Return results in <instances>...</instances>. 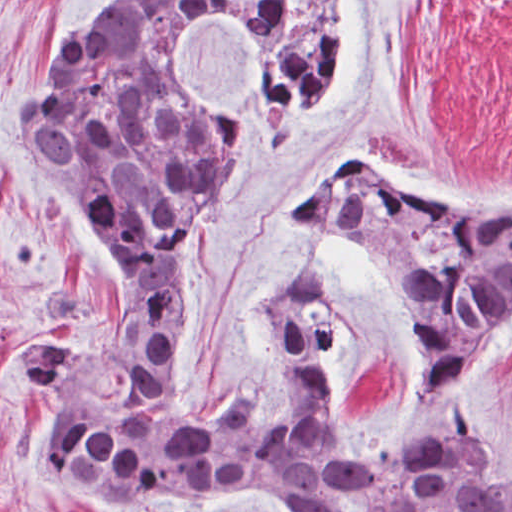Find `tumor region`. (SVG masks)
Instances as JSON below:
<instances>
[{
  "label": "tumor region",
  "instance_id": "e687c5a6",
  "mask_svg": "<svg viewBox=\"0 0 512 512\" xmlns=\"http://www.w3.org/2000/svg\"><path fill=\"white\" fill-rule=\"evenodd\" d=\"M344 7L144 0L60 38L34 74L19 135L78 211L126 302L113 325L27 344L10 366L53 400L38 462L98 512L149 493L229 491L263 512H332L339 493L379 512H512V464L471 426L473 379L512 348V204L470 206L344 163L291 214L356 226L392 270L414 316L412 390L393 425L366 430L337 404L341 304L316 254L262 285L265 328L299 419H270L235 396L215 418L193 421L173 398L185 255L225 199L239 129L188 51L203 30L231 34L263 112L297 145L343 95ZM27 301L46 319H88L96 304L59 275L36 278Z\"/></svg>",
  "mask_w": 512,
  "mask_h": 512
}]
</instances>
